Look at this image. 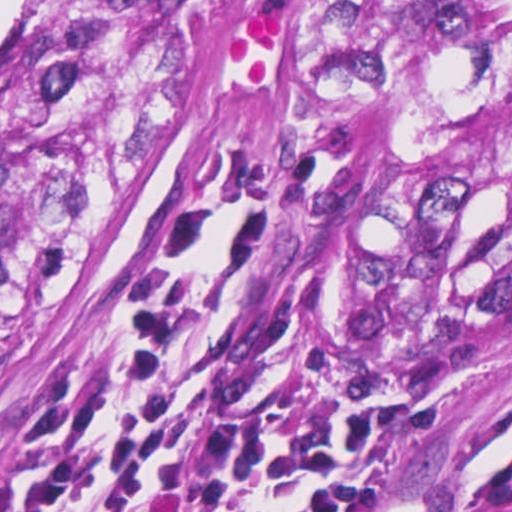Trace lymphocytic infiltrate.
<instances>
[{"label":"lymphocytic infiltrate","mask_w":512,"mask_h":512,"mask_svg":"<svg viewBox=\"0 0 512 512\" xmlns=\"http://www.w3.org/2000/svg\"><path fill=\"white\" fill-rule=\"evenodd\" d=\"M311 170L237 157L202 278L206 209L182 203L114 306L101 375L43 388L0 483V512H372L376 419L365 394L279 370L261 336V252Z\"/></svg>","instance_id":"lymphocytic-infiltrate-1"}]
</instances>
